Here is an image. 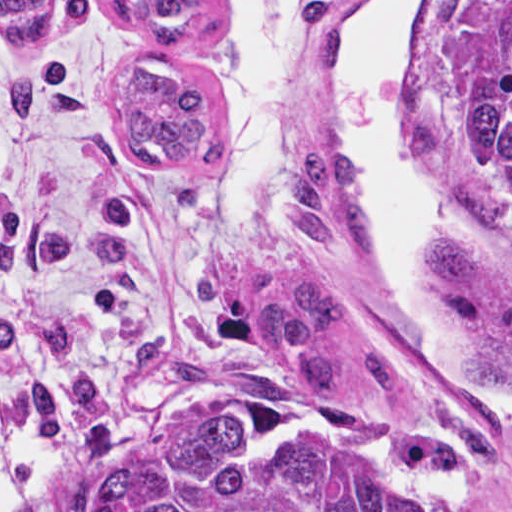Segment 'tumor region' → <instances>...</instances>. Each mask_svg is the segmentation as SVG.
I'll return each instance as SVG.
<instances>
[{
    "mask_svg": "<svg viewBox=\"0 0 512 512\" xmlns=\"http://www.w3.org/2000/svg\"><path fill=\"white\" fill-rule=\"evenodd\" d=\"M137 38L166 45L135 58L120 87V148L139 167H209L223 156L226 119L182 44L218 14L207 1H110ZM53 1H0V30L19 45L44 34ZM447 141L467 198L512 237V1H464L447 56ZM291 223L316 246L375 249L377 235L347 151L320 148L293 161ZM433 272L496 314L500 333L469 360L481 387L512 392V294L480 249L433 245ZM249 317L269 352L300 361L321 397L345 394L341 335L357 333L374 391H403V361L335 283L296 281L251 291ZM23 512H458L381 470L334 438L297 444L269 459L240 458L233 419L206 392L102 442L77 475L35 491Z\"/></svg>",
    "mask_w": 512,
    "mask_h": 512,
    "instance_id": "e687c5a6",
    "label": "tumor region"
}]
</instances>
